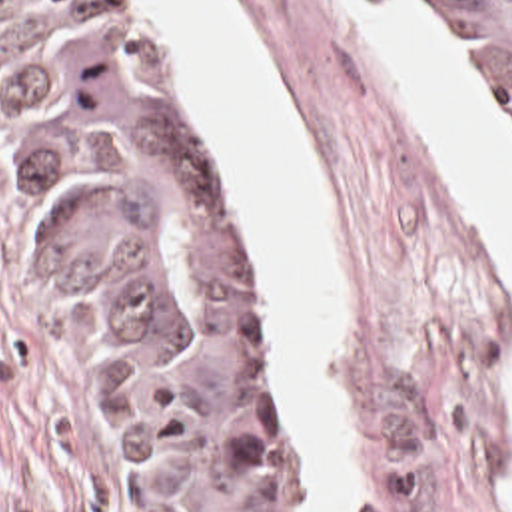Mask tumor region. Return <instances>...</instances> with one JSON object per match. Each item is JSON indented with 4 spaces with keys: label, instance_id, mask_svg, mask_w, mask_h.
Returning <instances> with one entry per match:
<instances>
[{
    "label": "tumor region",
    "instance_id": "tumor-region-1",
    "mask_svg": "<svg viewBox=\"0 0 512 512\" xmlns=\"http://www.w3.org/2000/svg\"><path fill=\"white\" fill-rule=\"evenodd\" d=\"M444 13L512 131V0ZM7 147L83 297L155 512H303L217 169L115 0H0Z\"/></svg>",
    "mask_w": 512,
    "mask_h": 512
}]
</instances>
